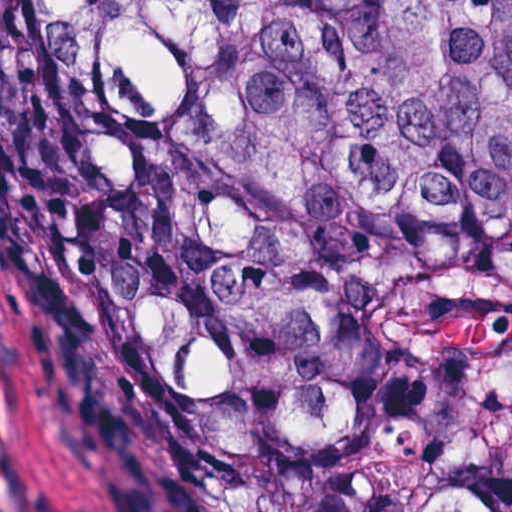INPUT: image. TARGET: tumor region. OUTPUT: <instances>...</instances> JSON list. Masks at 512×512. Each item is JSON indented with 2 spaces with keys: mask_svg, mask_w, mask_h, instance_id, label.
Wrapping results in <instances>:
<instances>
[{
  "mask_svg": "<svg viewBox=\"0 0 512 512\" xmlns=\"http://www.w3.org/2000/svg\"><path fill=\"white\" fill-rule=\"evenodd\" d=\"M0 132L157 512H512V0H0Z\"/></svg>",
  "mask_w": 512,
  "mask_h": 512,
  "instance_id": "obj_1",
  "label": "tumor region"
}]
</instances>
